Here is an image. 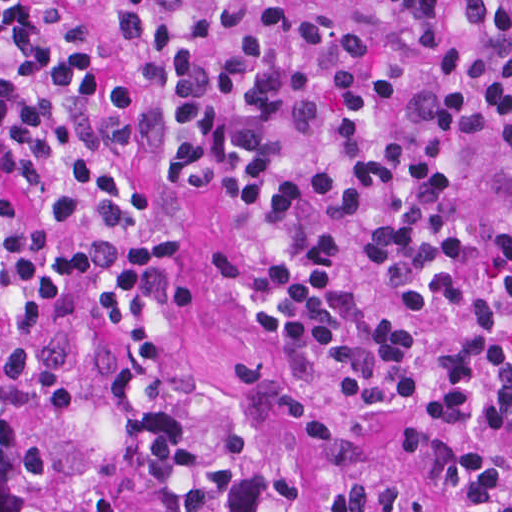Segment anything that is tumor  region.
I'll list each match as a JSON object with an SVG mask.
<instances>
[{
	"instance_id": "tumor-region-1",
	"label": "tumor region",
	"mask_w": 512,
	"mask_h": 512,
	"mask_svg": "<svg viewBox=\"0 0 512 512\" xmlns=\"http://www.w3.org/2000/svg\"><path fill=\"white\" fill-rule=\"evenodd\" d=\"M316 448L384 465L302 424ZM291 461L267 439L212 479L125 341L67 296L0 267V512H294ZM337 512H446L419 491L347 481Z\"/></svg>"
}]
</instances>
